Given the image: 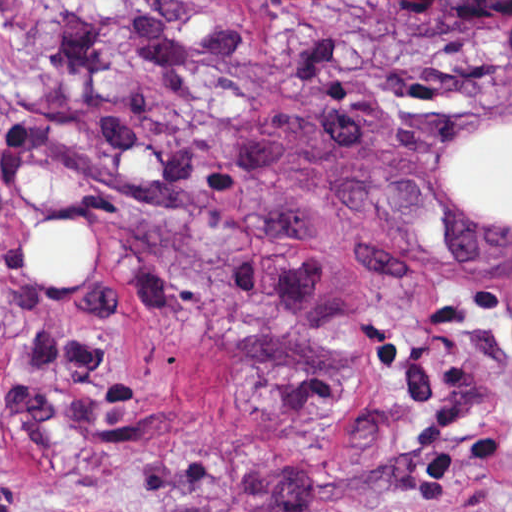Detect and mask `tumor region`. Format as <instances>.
I'll return each mask as SVG.
<instances>
[{"instance_id":"tumor-region-1","label":"tumor region","mask_w":512,"mask_h":512,"mask_svg":"<svg viewBox=\"0 0 512 512\" xmlns=\"http://www.w3.org/2000/svg\"><path fill=\"white\" fill-rule=\"evenodd\" d=\"M398 39L429 49L487 42L512 22V0H335Z\"/></svg>"}]
</instances>
